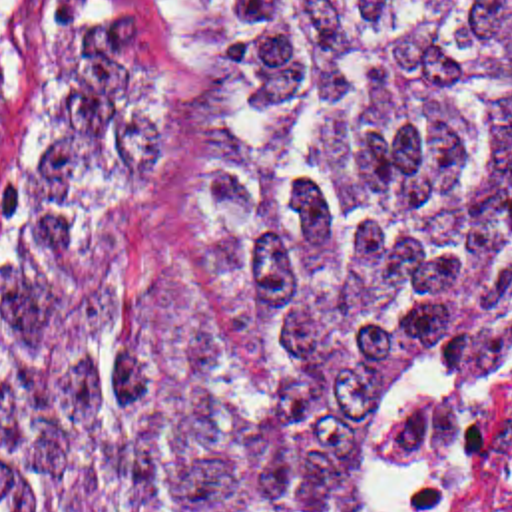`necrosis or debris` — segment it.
Here are the masks:
<instances>
[{
    "label": "necrosis or debris",
    "mask_w": 512,
    "mask_h": 512,
    "mask_svg": "<svg viewBox=\"0 0 512 512\" xmlns=\"http://www.w3.org/2000/svg\"><path fill=\"white\" fill-rule=\"evenodd\" d=\"M267 512H512V400L349 412Z\"/></svg>",
    "instance_id": "necrosis-or-debris-1"
}]
</instances>
